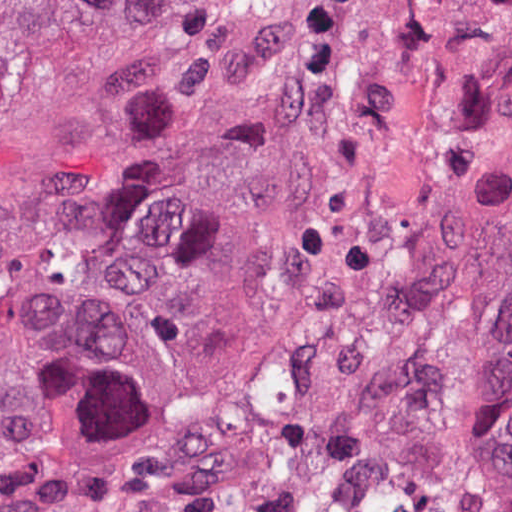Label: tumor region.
I'll list each match as a JSON object with an SVG mask.
<instances>
[{"label":"tumor region","instance_id":"obj_1","mask_svg":"<svg viewBox=\"0 0 512 512\" xmlns=\"http://www.w3.org/2000/svg\"><path fill=\"white\" fill-rule=\"evenodd\" d=\"M49 0H0V54L5 44L35 11Z\"/></svg>","mask_w":512,"mask_h":512}]
</instances>
